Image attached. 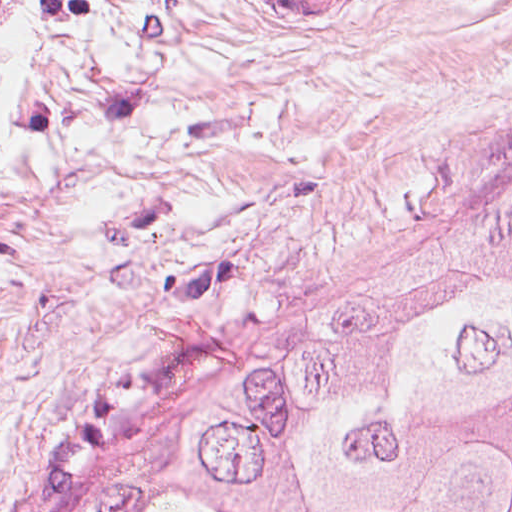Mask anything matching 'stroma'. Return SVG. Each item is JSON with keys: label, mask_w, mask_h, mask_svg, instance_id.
I'll use <instances>...</instances> for the list:
<instances>
[{"label": "stroma", "mask_w": 512, "mask_h": 512, "mask_svg": "<svg viewBox=\"0 0 512 512\" xmlns=\"http://www.w3.org/2000/svg\"><path fill=\"white\" fill-rule=\"evenodd\" d=\"M498 218L512 0H0V512H77Z\"/></svg>", "instance_id": "stroma-1"}]
</instances>
